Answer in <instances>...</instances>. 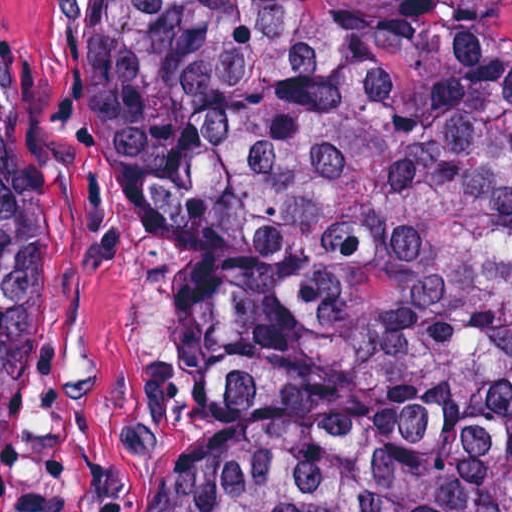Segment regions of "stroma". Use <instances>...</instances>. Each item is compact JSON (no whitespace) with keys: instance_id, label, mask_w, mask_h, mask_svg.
<instances>
[{"instance_id":"35a3bbf8","label":"stroma","mask_w":512,"mask_h":512,"mask_svg":"<svg viewBox=\"0 0 512 512\" xmlns=\"http://www.w3.org/2000/svg\"><path fill=\"white\" fill-rule=\"evenodd\" d=\"M107 1L0 0L46 76V291L38 349V512H140L170 443L209 415L175 359L181 251L108 173L79 123V58Z\"/></svg>"}]
</instances>
